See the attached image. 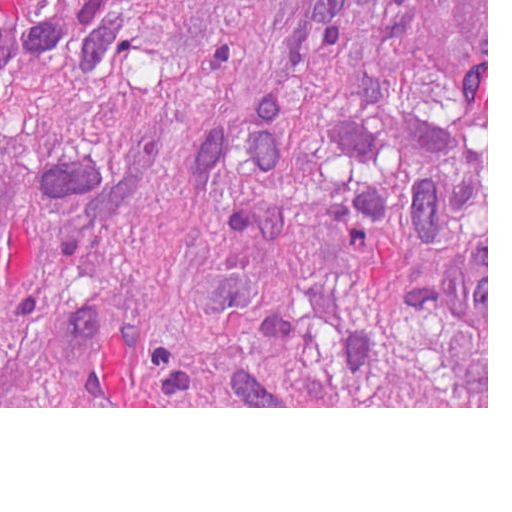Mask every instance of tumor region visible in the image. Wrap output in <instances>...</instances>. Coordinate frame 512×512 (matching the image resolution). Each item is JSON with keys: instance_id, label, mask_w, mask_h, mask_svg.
Listing matches in <instances>:
<instances>
[{"instance_id": "1", "label": "tumor region", "mask_w": 512, "mask_h": 512, "mask_svg": "<svg viewBox=\"0 0 512 512\" xmlns=\"http://www.w3.org/2000/svg\"><path fill=\"white\" fill-rule=\"evenodd\" d=\"M0 407H487V0H0Z\"/></svg>"}]
</instances>
